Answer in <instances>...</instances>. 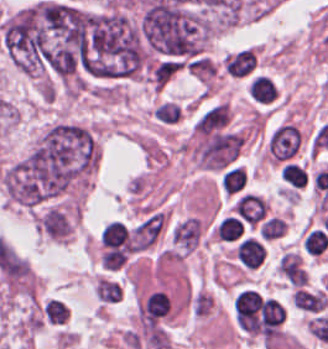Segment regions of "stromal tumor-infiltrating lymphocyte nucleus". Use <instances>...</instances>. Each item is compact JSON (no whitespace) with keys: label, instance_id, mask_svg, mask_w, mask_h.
<instances>
[{"label":"stromal tumor-infiltrating lymphocyte nucleus","instance_id":"obj_6","mask_svg":"<svg viewBox=\"0 0 328 349\" xmlns=\"http://www.w3.org/2000/svg\"><path fill=\"white\" fill-rule=\"evenodd\" d=\"M71 312L67 303L56 298H49L42 309L41 315L48 324L61 325Z\"/></svg>","mask_w":328,"mask_h":349},{"label":"stromal tumor-infiltrating lymphocyte nucleus","instance_id":"obj_4","mask_svg":"<svg viewBox=\"0 0 328 349\" xmlns=\"http://www.w3.org/2000/svg\"><path fill=\"white\" fill-rule=\"evenodd\" d=\"M247 183V174L241 165L234 164L226 169L220 178V186L227 194H241Z\"/></svg>","mask_w":328,"mask_h":349},{"label":"stromal tumor-infiltrating lymphocyte nucleus","instance_id":"obj_11","mask_svg":"<svg viewBox=\"0 0 328 349\" xmlns=\"http://www.w3.org/2000/svg\"><path fill=\"white\" fill-rule=\"evenodd\" d=\"M281 178L291 186H304L306 176L304 170L294 163L284 164L281 168Z\"/></svg>","mask_w":328,"mask_h":349},{"label":"stromal tumor-infiltrating lymphocyte nucleus","instance_id":"obj_2","mask_svg":"<svg viewBox=\"0 0 328 349\" xmlns=\"http://www.w3.org/2000/svg\"><path fill=\"white\" fill-rule=\"evenodd\" d=\"M277 271L294 287L308 283V276L298 253L286 252L281 256Z\"/></svg>","mask_w":328,"mask_h":349},{"label":"stromal tumor-infiltrating lymphocyte nucleus","instance_id":"obj_8","mask_svg":"<svg viewBox=\"0 0 328 349\" xmlns=\"http://www.w3.org/2000/svg\"><path fill=\"white\" fill-rule=\"evenodd\" d=\"M153 117L158 123L171 125L181 118V110L176 101L163 100L153 109Z\"/></svg>","mask_w":328,"mask_h":349},{"label":"stromal tumor-infiltrating lymphocyte nucleus","instance_id":"obj_1","mask_svg":"<svg viewBox=\"0 0 328 349\" xmlns=\"http://www.w3.org/2000/svg\"><path fill=\"white\" fill-rule=\"evenodd\" d=\"M248 96L257 104H272L277 98L275 85L266 75L253 74L247 80Z\"/></svg>","mask_w":328,"mask_h":349},{"label":"stromal tumor-infiltrating lymphocyte nucleus","instance_id":"obj_3","mask_svg":"<svg viewBox=\"0 0 328 349\" xmlns=\"http://www.w3.org/2000/svg\"><path fill=\"white\" fill-rule=\"evenodd\" d=\"M235 257L246 268H255L263 262L264 247L250 238L238 242Z\"/></svg>","mask_w":328,"mask_h":349},{"label":"stromal tumor-infiltrating lymphocyte nucleus","instance_id":"obj_5","mask_svg":"<svg viewBox=\"0 0 328 349\" xmlns=\"http://www.w3.org/2000/svg\"><path fill=\"white\" fill-rule=\"evenodd\" d=\"M328 299L319 293L296 289L292 295V303L294 306L310 312H318L323 310Z\"/></svg>","mask_w":328,"mask_h":349},{"label":"stromal tumor-infiltrating lymphocyte nucleus","instance_id":"obj_7","mask_svg":"<svg viewBox=\"0 0 328 349\" xmlns=\"http://www.w3.org/2000/svg\"><path fill=\"white\" fill-rule=\"evenodd\" d=\"M100 239L106 246H125L128 232L122 221L112 220L101 230Z\"/></svg>","mask_w":328,"mask_h":349},{"label":"stromal tumor-infiltrating lymphocyte nucleus","instance_id":"obj_10","mask_svg":"<svg viewBox=\"0 0 328 349\" xmlns=\"http://www.w3.org/2000/svg\"><path fill=\"white\" fill-rule=\"evenodd\" d=\"M303 244L309 252L321 254L328 247V232L313 229L308 232Z\"/></svg>","mask_w":328,"mask_h":349},{"label":"stromal tumor-infiltrating lymphocyte nucleus","instance_id":"obj_9","mask_svg":"<svg viewBox=\"0 0 328 349\" xmlns=\"http://www.w3.org/2000/svg\"><path fill=\"white\" fill-rule=\"evenodd\" d=\"M243 226L236 217L226 216L217 226L215 234L220 241H234L241 237Z\"/></svg>","mask_w":328,"mask_h":349}]
</instances>
